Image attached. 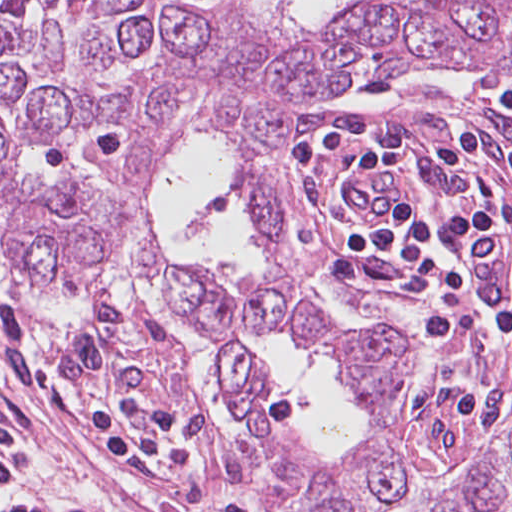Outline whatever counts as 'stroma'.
<instances>
[{"mask_svg":"<svg viewBox=\"0 0 512 512\" xmlns=\"http://www.w3.org/2000/svg\"><path fill=\"white\" fill-rule=\"evenodd\" d=\"M445 83L459 84L465 106L480 125V170L450 168L427 155L397 178L364 177L344 186V213L357 221L377 222L399 199L453 212L482 204L494 193L504 226L480 246V258L512 293V112L503 108L489 84L512 91V72L502 67H441L423 75H364L300 103L283 126V192L292 208V255L302 272L303 295L347 319L390 328L407 346L398 371V439L412 463V482L385 512H444L449 505L441 496L468 479L512 421V335L474 345L487 328L480 304L455 299L429 280L381 259L355 249L349 253L330 233L338 184L361 153L382 145L420 153L453 130L455 113ZM332 111L313 168L312 204L302 224V143L309 125ZM99 284L61 295L26 291L36 298H55ZM0 301L28 326L50 332L37 327L11 297L0 292ZM172 304L218 362L214 348L195 335ZM65 332L95 345L165 354L179 363L187 379L180 413L195 442L221 467L215 450L237 437L239 425L235 392L219 362L234 437L203 412L189 364L148 301L102 294L93 300L88 316ZM472 394L507 397L486 421L460 400ZM0 460L95 512H160L123 467L80 448L64 413L2 378ZM248 496L256 512H269Z\"/></svg>","mask_w":512,"mask_h":512,"instance_id":"obj_1","label":"stroma"}]
</instances>
